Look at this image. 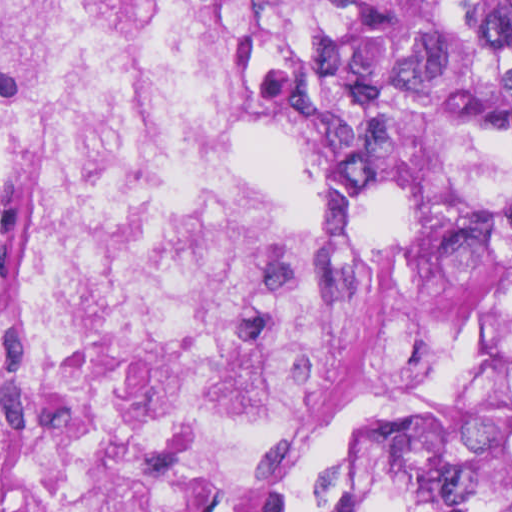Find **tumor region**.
Returning <instances> with one entry per match:
<instances>
[{
    "mask_svg": "<svg viewBox=\"0 0 512 512\" xmlns=\"http://www.w3.org/2000/svg\"><path fill=\"white\" fill-rule=\"evenodd\" d=\"M284 140L379 197H509L512 0H228ZM413 512H512V415L420 486Z\"/></svg>",
    "mask_w": 512,
    "mask_h": 512,
    "instance_id": "e687c5a6",
    "label": "tumor region"
}]
</instances>
